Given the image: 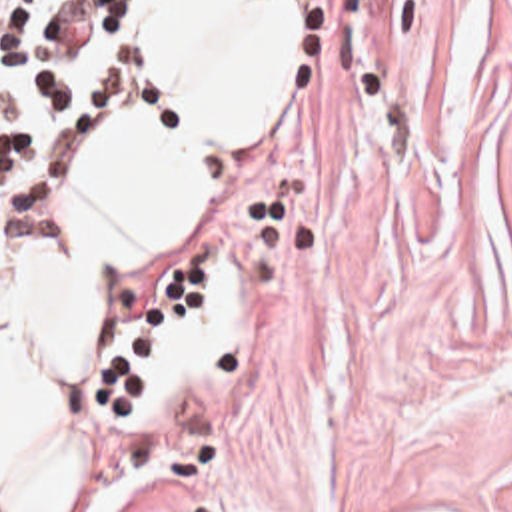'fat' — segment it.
Masks as SVG:
<instances>
[{"mask_svg": "<svg viewBox=\"0 0 512 512\" xmlns=\"http://www.w3.org/2000/svg\"><path fill=\"white\" fill-rule=\"evenodd\" d=\"M304 60V0H168V136L148 196L80 268L0 386V512H118L126 491L88 456L86 340L114 286L180 254L286 118Z\"/></svg>", "mask_w": 512, "mask_h": 512, "instance_id": "53f6f03d", "label": "fat"}]
</instances>
